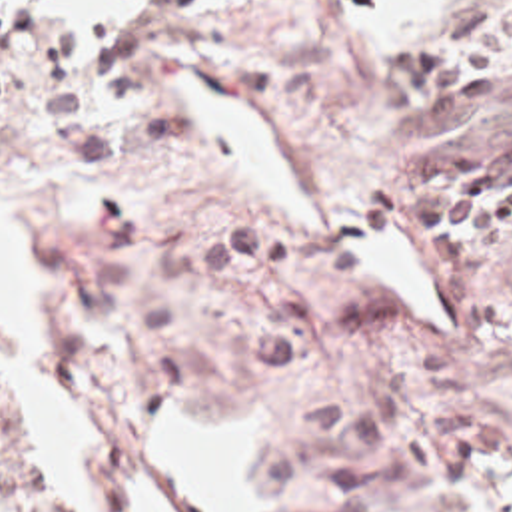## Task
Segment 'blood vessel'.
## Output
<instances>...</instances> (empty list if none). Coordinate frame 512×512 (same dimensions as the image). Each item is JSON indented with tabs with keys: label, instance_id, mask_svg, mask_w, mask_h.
<instances>
[{
	"label": "blood vessel",
	"instance_id": "obj_1",
	"mask_svg": "<svg viewBox=\"0 0 512 512\" xmlns=\"http://www.w3.org/2000/svg\"><path fill=\"white\" fill-rule=\"evenodd\" d=\"M123 492H125V500H127L131 512H167L165 506L155 496L151 484L137 476L127 474Z\"/></svg>",
	"mask_w": 512,
	"mask_h": 512
}]
</instances>
